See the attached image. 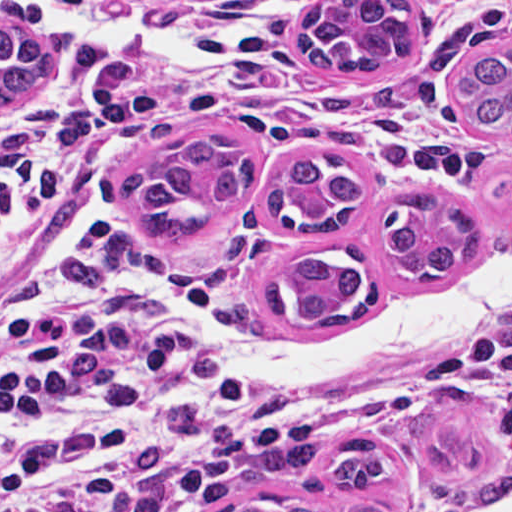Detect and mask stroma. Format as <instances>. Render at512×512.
Returning <instances> with one entry per match:
<instances>
[{"instance_id": "35a3bbf8", "label": "stroma", "mask_w": 512, "mask_h": 512, "mask_svg": "<svg viewBox=\"0 0 512 512\" xmlns=\"http://www.w3.org/2000/svg\"><path fill=\"white\" fill-rule=\"evenodd\" d=\"M17 29L34 39L47 26ZM111 7L173 28L211 22L221 60L212 65L148 52L94 49L74 32L52 76L24 99L0 106V281L34 255L98 240H125L174 262L183 304L214 323L249 333L332 337L371 312L441 303L470 261L433 284H403L381 258L385 206L433 188L481 218V247L512 226V132L476 129L456 93L475 54L512 45V0H412L414 53L367 71H317L289 44L308 8L327 0H58ZM4 27V26H3ZM205 124L246 141L254 181L229 211H215L196 246H163L140 233L118 200L130 173L165 159L171 143ZM303 155L350 161L363 198L337 229L284 231L267 207L282 166ZM298 247L356 249L367 272L361 303L323 325L279 318L266 305L272 278ZM512 275L492 285V299ZM483 322L449 345L391 358L302 388H270L344 415L291 460L209 501L224 512L253 497L370 504L381 512H464L478 505L432 497L426 467L407 440L406 421L432 393L464 389L480 398L486 455L512 468V391L486 361ZM378 440L395 470L378 489H332L326 465L345 441Z\"/></svg>"}]
</instances>
